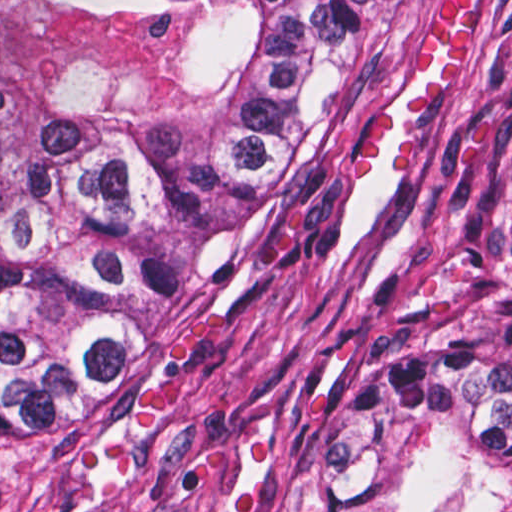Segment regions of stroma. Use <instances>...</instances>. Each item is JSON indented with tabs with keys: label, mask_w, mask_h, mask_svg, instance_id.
Instances as JSON below:
<instances>
[{
	"label": "stroma",
	"mask_w": 512,
	"mask_h": 512,
	"mask_svg": "<svg viewBox=\"0 0 512 512\" xmlns=\"http://www.w3.org/2000/svg\"><path fill=\"white\" fill-rule=\"evenodd\" d=\"M441 0H367L341 121L290 203L238 243L88 461L0 512H330L331 438L418 340L512 291V0L470 58L404 92L364 182L356 124Z\"/></svg>",
	"instance_id": "1"
}]
</instances>
